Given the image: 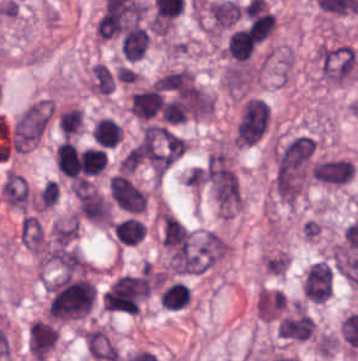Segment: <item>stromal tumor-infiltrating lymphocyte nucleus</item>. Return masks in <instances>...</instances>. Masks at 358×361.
I'll return each instance as SVG.
<instances>
[{"instance_id": "obj_3", "label": "stromal tumor-infiltrating lymphocyte nucleus", "mask_w": 358, "mask_h": 361, "mask_svg": "<svg viewBox=\"0 0 358 361\" xmlns=\"http://www.w3.org/2000/svg\"><path fill=\"white\" fill-rule=\"evenodd\" d=\"M160 240L166 251L191 242V231L171 212H164L160 220Z\"/></svg>"}, {"instance_id": "obj_5", "label": "stromal tumor-infiltrating lymphocyte nucleus", "mask_w": 358, "mask_h": 361, "mask_svg": "<svg viewBox=\"0 0 358 361\" xmlns=\"http://www.w3.org/2000/svg\"><path fill=\"white\" fill-rule=\"evenodd\" d=\"M111 229L117 243L121 245H133L145 235L144 221L133 215H126L117 220Z\"/></svg>"}, {"instance_id": "obj_2", "label": "stromal tumor-infiltrating lymphocyte nucleus", "mask_w": 358, "mask_h": 361, "mask_svg": "<svg viewBox=\"0 0 358 361\" xmlns=\"http://www.w3.org/2000/svg\"><path fill=\"white\" fill-rule=\"evenodd\" d=\"M140 16V2L124 5L100 14L95 30L101 38L118 35Z\"/></svg>"}, {"instance_id": "obj_8", "label": "stromal tumor-infiltrating lymphocyte nucleus", "mask_w": 358, "mask_h": 361, "mask_svg": "<svg viewBox=\"0 0 358 361\" xmlns=\"http://www.w3.org/2000/svg\"><path fill=\"white\" fill-rule=\"evenodd\" d=\"M189 289L180 281H172L160 294V301L165 307L178 309L188 303Z\"/></svg>"}, {"instance_id": "obj_4", "label": "stromal tumor-infiltrating lymphocyte nucleus", "mask_w": 358, "mask_h": 361, "mask_svg": "<svg viewBox=\"0 0 358 361\" xmlns=\"http://www.w3.org/2000/svg\"><path fill=\"white\" fill-rule=\"evenodd\" d=\"M149 42V36L138 24H130L122 33L119 52L128 60L134 61L143 56Z\"/></svg>"}, {"instance_id": "obj_1", "label": "stromal tumor-infiltrating lymphocyte nucleus", "mask_w": 358, "mask_h": 361, "mask_svg": "<svg viewBox=\"0 0 358 361\" xmlns=\"http://www.w3.org/2000/svg\"><path fill=\"white\" fill-rule=\"evenodd\" d=\"M58 340L55 323L48 318H40L29 323L26 332V348L30 357L43 361Z\"/></svg>"}, {"instance_id": "obj_6", "label": "stromal tumor-infiltrating lymphocyte nucleus", "mask_w": 358, "mask_h": 361, "mask_svg": "<svg viewBox=\"0 0 358 361\" xmlns=\"http://www.w3.org/2000/svg\"><path fill=\"white\" fill-rule=\"evenodd\" d=\"M157 94L150 87L135 92L129 98V112L139 120H147L158 112Z\"/></svg>"}, {"instance_id": "obj_7", "label": "stromal tumor-infiltrating lymphocyte nucleus", "mask_w": 358, "mask_h": 361, "mask_svg": "<svg viewBox=\"0 0 358 361\" xmlns=\"http://www.w3.org/2000/svg\"><path fill=\"white\" fill-rule=\"evenodd\" d=\"M57 124L64 137H74L83 128L82 110L75 105H68L60 109Z\"/></svg>"}]
</instances>
